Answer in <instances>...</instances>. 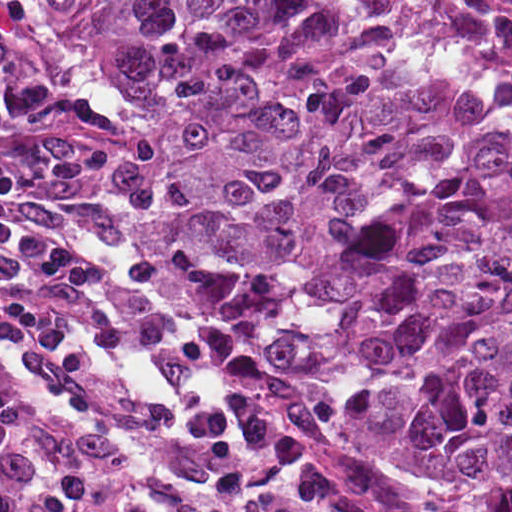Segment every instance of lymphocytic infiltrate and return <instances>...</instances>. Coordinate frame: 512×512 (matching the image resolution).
Segmentation results:
<instances>
[{"mask_svg": "<svg viewBox=\"0 0 512 512\" xmlns=\"http://www.w3.org/2000/svg\"><path fill=\"white\" fill-rule=\"evenodd\" d=\"M135 129L70 67L0 27V186Z\"/></svg>", "mask_w": 512, "mask_h": 512, "instance_id": "1", "label": "lymphocytic infiltrate"}]
</instances>
